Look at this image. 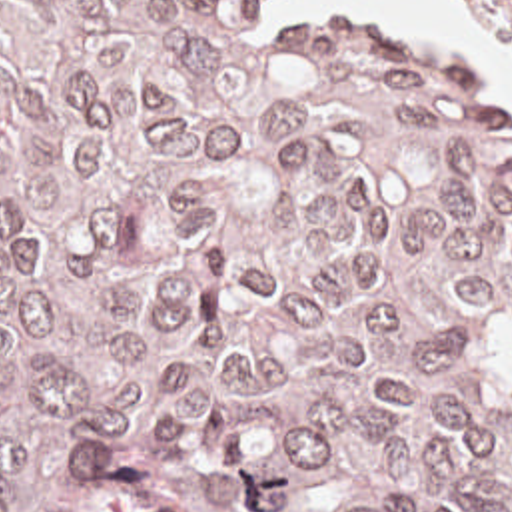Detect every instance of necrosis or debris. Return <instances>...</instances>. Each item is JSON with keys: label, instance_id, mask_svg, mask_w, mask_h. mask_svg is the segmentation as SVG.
<instances>
[{"label": "necrosis or debris", "instance_id": "4bbe7bcc", "mask_svg": "<svg viewBox=\"0 0 512 512\" xmlns=\"http://www.w3.org/2000/svg\"><path fill=\"white\" fill-rule=\"evenodd\" d=\"M512 48V0H460Z\"/></svg>", "mask_w": 512, "mask_h": 512}]
</instances>
